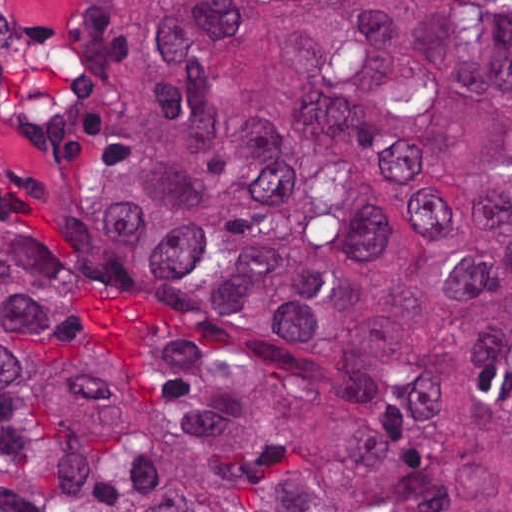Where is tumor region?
Returning a JSON list of instances; mask_svg holds the SVG:
<instances>
[{"label":"tumor region","instance_id":"e687c5a6","mask_svg":"<svg viewBox=\"0 0 512 512\" xmlns=\"http://www.w3.org/2000/svg\"><path fill=\"white\" fill-rule=\"evenodd\" d=\"M102 276L0 216V512H512V0H117Z\"/></svg>","mask_w":512,"mask_h":512}]
</instances>
